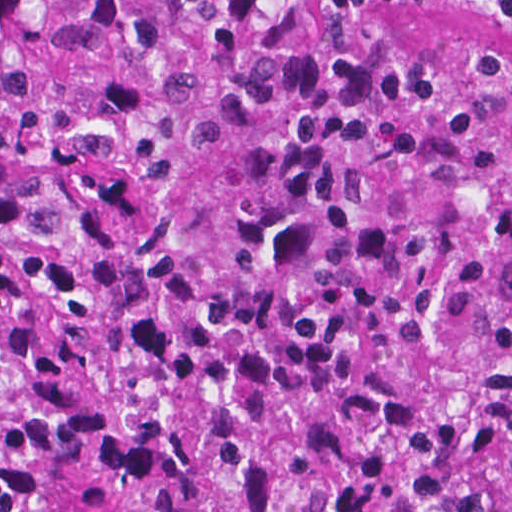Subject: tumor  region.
<instances>
[{"instance_id": "tumor-region-1", "label": "tumor region", "mask_w": 512, "mask_h": 512, "mask_svg": "<svg viewBox=\"0 0 512 512\" xmlns=\"http://www.w3.org/2000/svg\"><path fill=\"white\" fill-rule=\"evenodd\" d=\"M293 1L0 0V512H512V68Z\"/></svg>"}]
</instances>
